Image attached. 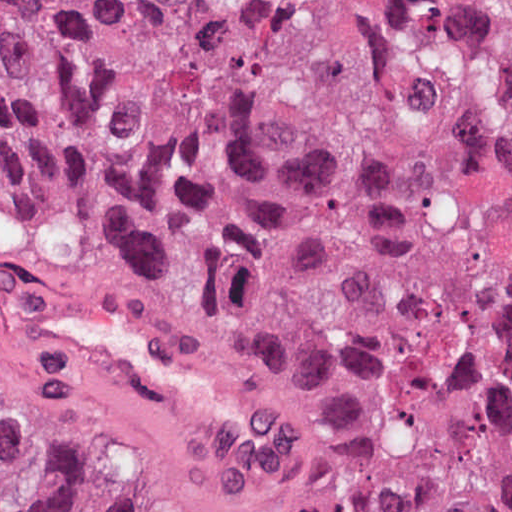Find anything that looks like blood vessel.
I'll return each mask as SVG.
<instances>
[{
    "label": "blood vessel",
    "instance_id": "8fb6f2fc",
    "mask_svg": "<svg viewBox=\"0 0 512 512\" xmlns=\"http://www.w3.org/2000/svg\"><path fill=\"white\" fill-rule=\"evenodd\" d=\"M39 289L63 341L112 369L236 427L254 422L250 401L226 373L129 307L73 290Z\"/></svg>",
    "mask_w": 512,
    "mask_h": 512
}]
</instances>
